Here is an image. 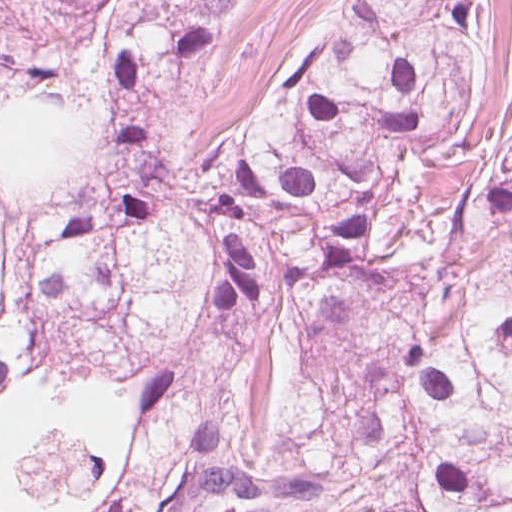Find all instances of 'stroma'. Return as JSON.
Listing matches in <instances>:
<instances>
[{
    "label": "stroma",
    "mask_w": 512,
    "mask_h": 512,
    "mask_svg": "<svg viewBox=\"0 0 512 512\" xmlns=\"http://www.w3.org/2000/svg\"><path fill=\"white\" fill-rule=\"evenodd\" d=\"M340 0H243L212 33L185 123L200 168L218 171L248 126L259 89L339 10ZM496 25L461 142L478 153L497 136L512 95V0Z\"/></svg>",
    "instance_id": "35a3bbf8"
}]
</instances>
